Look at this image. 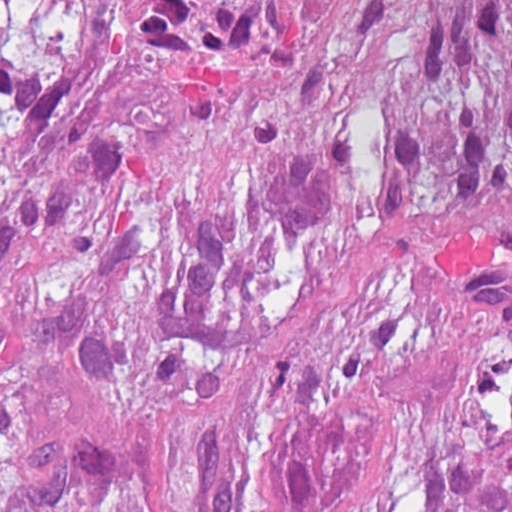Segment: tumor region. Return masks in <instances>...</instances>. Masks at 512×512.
Instances as JSON below:
<instances>
[{
    "mask_svg": "<svg viewBox=\"0 0 512 512\" xmlns=\"http://www.w3.org/2000/svg\"><path fill=\"white\" fill-rule=\"evenodd\" d=\"M0 512H512V3L0 19Z\"/></svg>",
    "mask_w": 512,
    "mask_h": 512,
    "instance_id": "tumor-region-1",
    "label": "tumor region"
}]
</instances>
